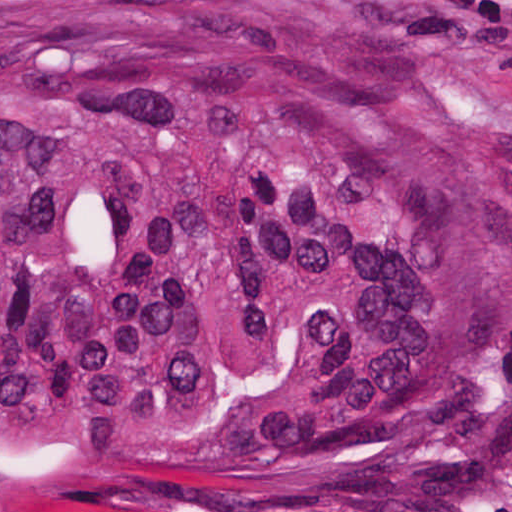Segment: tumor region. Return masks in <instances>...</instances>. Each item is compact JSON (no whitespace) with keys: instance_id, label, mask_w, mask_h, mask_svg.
Listing matches in <instances>:
<instances>
[{"instance_id":"e687c5a6","label":"tumor region","mask_w":512,"mask_h":512,"mask_svg":"<svg viewBox=\"0 0 512 512\" xmlns=\"http://www.w3.org/2000/svg\"><path fill=\"white\" fill-rule=\"evenodd\" d=\"M512 404V166L277 0H0V512L421 472Z\"/></svg>"}]
</instances>
